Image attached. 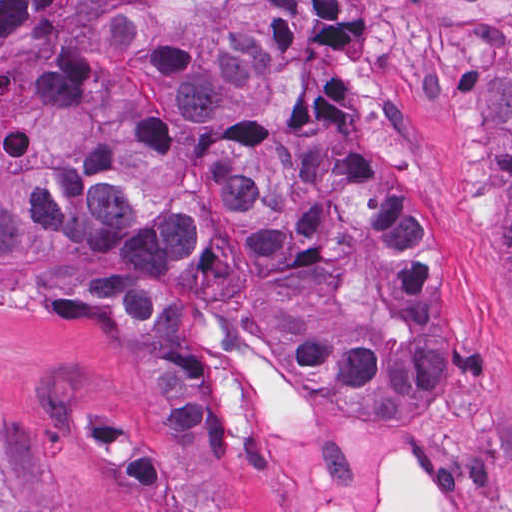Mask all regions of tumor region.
Instances as JSON below:
<instances>
[{
    "label": "tumor region",
    "instance_id": "obj_1",
    "mask_svg": "<svg viewBox=\"0 0 512 512\" xmlns=\"http://www.w3.org/2000/svg\"><path fill=\"white\" fill-rule=\"evenodd\" d=\"M259 0H0V272L128 321L162 449L72 415L69 437L145 512H238L213 361L184 301L231 316L335 412L426 416L452 384L450 307L424 215L378 164L282 123ZM350 0H267V65L356 129ZM512 334V57L471 97ZM0 512H39L0 486Z\"/></svg>",
    "mask_w": 512,
    "mask_h": 512
}]
</instances>
